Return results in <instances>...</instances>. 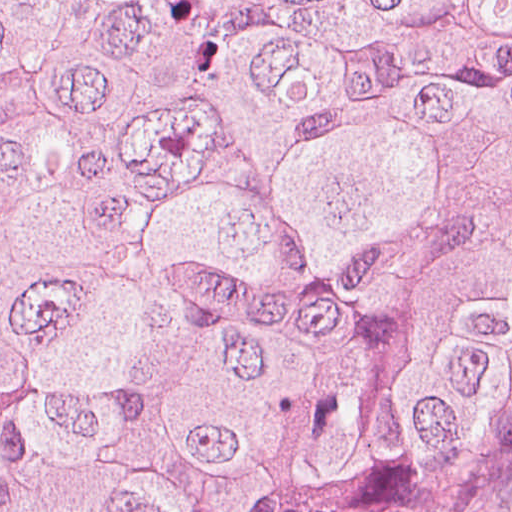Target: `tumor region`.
I'll list each match as a JSON object with an SVG mask.
<instances>
[{"label":"tumor region","mask_w":512,"mask_h":512,"mask_svg":"<svg viewBox=\"0 0 512 512\" xmlns=\"http://www.w3.org/2000/svg\"><path fill=\"white\" fill-rule=\"evenodd\" d=\"M510 483L512 0H0V512Z\"/></svg>","instance_id":"tumor-region-1"}]
</instances>
